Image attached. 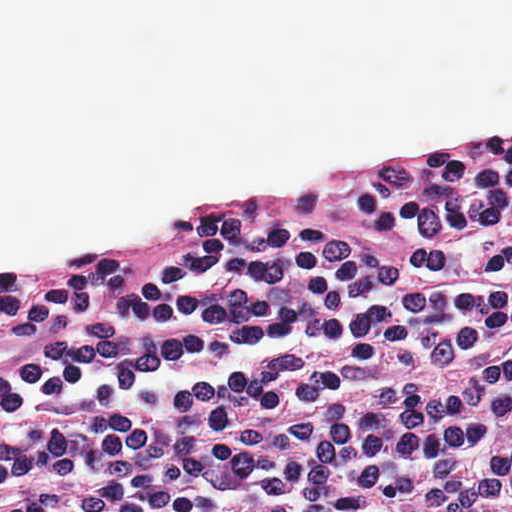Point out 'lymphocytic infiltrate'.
Returning a JSON list of instances; mask_svg holds the SVG:
<instances>
[{"instance_id": "1", "label": "lymphocytic infiltrate", "mask_w": 512, "mask_h": 512, "mask_svg": "<svg viewBox=\"0 0 512 512\" xmlns=\"http://www.w3.org/2000/svg\"><path fill=\"white\" fill-rule=\"evenodd\" d=\"M0 512H512V133L0 274Z\"/></svg>"}]
</instances>
